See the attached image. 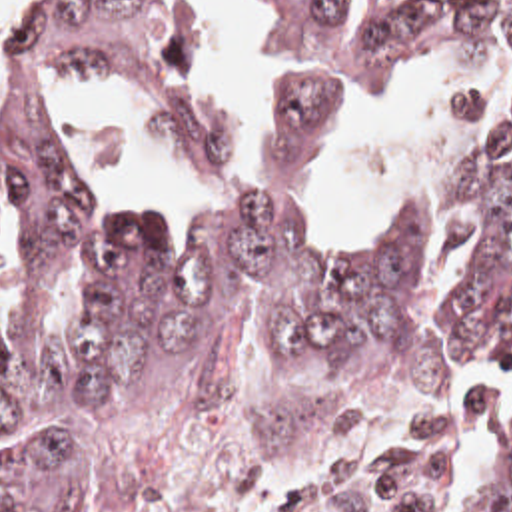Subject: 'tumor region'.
Segmentation results:
<instances>
[{
    "instance_id": "obj_1",
    "label": "tumor region",
    "mask_w": 512,
    "mask_h": 512,
    "mask_svg": "<svg viewBox=\"0 0 512 512\" xmlns=\"http://www.w3.org/2000/svg\"><path fill=\"white\" fill-rule=\"evenodd\" d=\"M467 34L499 46L509 114L469 178V270L431 318L425 250L401 234L325 252L303 174L319 130ZM281 46L293 124L265 192L196 250L106 212L44 96L48 72L104 76L186 158L238 160L196 0H54L0 86L8 364L92 448L152 477L345 462L373 493L512 512V436L475 489L451 479L501 402L469 386V364L512 362V0H281ZM0 512L108 511L64 460L18 452L0 462Z\"/></svg>"
}]
</instances>
